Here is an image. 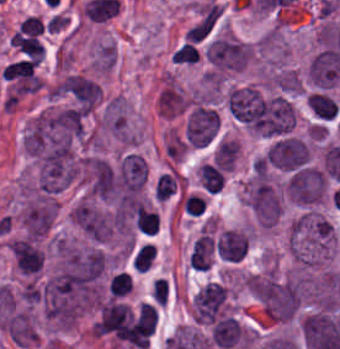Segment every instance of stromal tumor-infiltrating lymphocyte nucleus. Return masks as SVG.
Returning <instances> with one entry per match:
<instances>
[{"label":"stromal tumor-infiltrating lymphocyte nucleus","instance_id":"stromal-tumor-infiltrating-lymphocyte-nucleus-1","mask_svg":"<svg viewBox=\"0 0 340 349\" xmlns=\"http://www.w3.org/2000/svg\"><path fill=\"white\" fill-rule=\"evenodd\" d=\"M227 171L214 160L203 163L198 168V178L205 193H216L226 183Z\"/></svg>","mask_w":340,"mask_h":349},{"label":"stromal tumor-infiltrating lymphocyte nucleus","instance_id":"stromal-tumor-infiltrating-lymphocyte-nucleus-2","mask_svg":"<svg viewBox=\"0 0 340 349\" xmlns=\"http://www.w3.org/2000/svg\"><path fill=\"white\" fill-rule=\"evenodd\" d=\"M308 102L313 114L320 118L330 120L337 112L338 103L331 95L311 92L308 94Z\"/></svg>","mask_w":340,"mask_h":349},{"label":"stromal tumor-infiltrating lymphocyte nucleus","instance_id":"stromal-tumor-infiltrating-lymphocyte-nucleus-3","mask_svg":"<svg viewBox=\"0 0 340 349\" xmlns=\"http://www.w3.org/2000/svg\"><path fill=\"white\" fill-rule=\"evenodd\" d=\"M178 179L173 171L162 173L155 182V199L167 201L177 195Z\"/></svg>","mask_w":340,"mask_h":349},{"label":"stromal tumor-infiltrating lymphocyte nucleus","instance_id":"stromal-tumor-infiltrating-lymphocyte-nucleus-4","mask_svg":"<svg viewBox=\"0 0 340 349\" xmlns=\"http://www.w3.org/2000/svg\"><path fill=\"white\" fill-rule=\"evenodd\" d=\"M179 203L183 214L188 216H201L208 209V202L204 194L187 193L180 199Z\"/></svg>","mask_w":340,"mask_h":349},{"label":"stromal tumor-infiltrating lymphocyte nucleus","instance_id":"stromal-tumor-infiltrating-lymphocyte-nucleus-5","mask_svg":"<svg viewBox=\"0 0 340 349\" xmlns=\"http://www.w3.org/2000/svg\"><path fill=\"white\" fill-rule=\"evenodd\" d=\"M154 256V250L151 242H144L136 250L132 260L134 267L146 271L150 268L152 259Z\"/></svg>","mask_w":340,"mask_h":349},{"label":"stromal tumor-infiltrating lymphocyte nucleus","instance_id":"stromal-tumor-infiltrating-lymphocyte-nucleus-6","mask_svg":"<svg viewBox=\"0 0 340 349\" xmlns=\"http://www.w3.org/2000/svg\"><path fill=\"white\" fill-rule=\"evenodd\" d=\"M130 291V277L125 273L113 274L108 281V294L110 296H124Z\"/></svg>","mask_w":340,"mask_h":349},{"label":"stromal tumor-infiltrating lymphocyte nucleus","instance_id":"stromal-tumor-infiltrating-lymphocyte-nucleus-7","mask_svg":"<svg viewBox=\"0 0 340 349\" xmlns=\"http://www.w3.org/2000/svg\"><path fill=\"white\" fill-rule=\"evenodd\" d=\"M199 53L193 42H185L177 47L173 53L172 61L179 63H195L198 61Z\"/></svg>","mask_w":340,"mask_h":349}]
</instances>
